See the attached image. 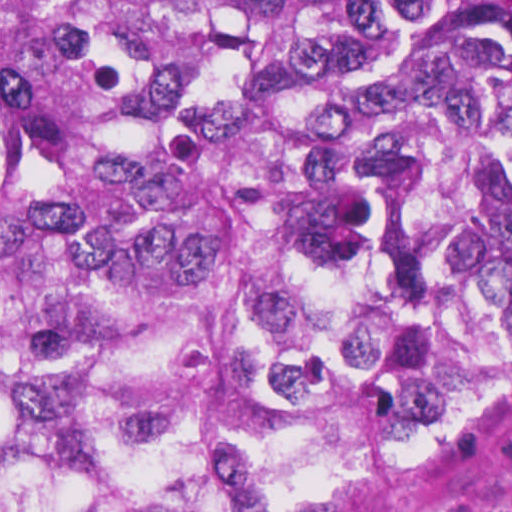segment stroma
Listing matches in <instances>:
<instances>
[{
    "mask_svg": "<svg viewBox=\"0 0 512 512\" xmlns=\"http://www.w3.org/2000/svg\"><path fill=\"white\" fill-rule=\"evenodd\" d=\"M0 1H512V0H0ZM341 512V511H339ZM375 512H512V411L389 506Z\"/></svg>",
    "mask_w": 512,
    "mask_h": 512,
    "instance_id": "obj_1",
    "label": "stroma"
}]
</instances>
